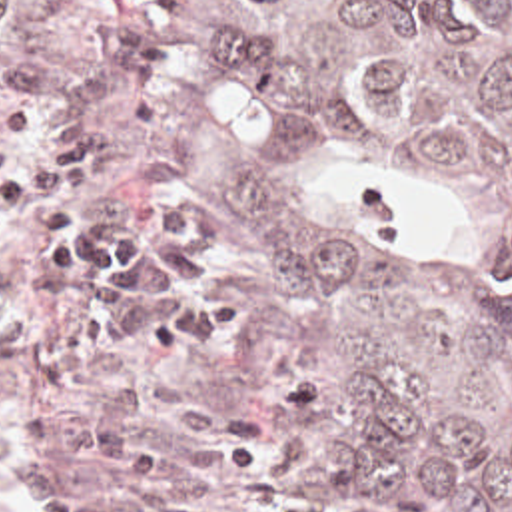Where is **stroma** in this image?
<instances>
[{
  "label": "stroma",
  "mask_w": 512,
  "mask_h": 512,
  "mask_svg": "<svg viewBox=\"0 0 512 512\" xmlns=\"http://www.w3.org/2000/svg\"><path fill=\"white\" fill-rule=\"evenodd\" d=\"M113 14L137 16L147 26L158 69L105 139L143 97L154 101L156 117L145 137L97 171L91 203L158 197L194 211L208 225L214 257L242 299L236 323L208 345L164 347L119 369L89 371L95 383H127L145 391L149 415L137 429L135 449H150L186 399L218 395L244 409L264 443L262 469L216 491L218 512H324L342 503L370 512H424L364 447L338 433L300 427L258 401L254 305L262 289V239L216 207L168 153L190 131H234L346 201L386 255L408 267L444 261V235L382 203L372 161L360 151L314 133L268 97L226 39L222 18L198 0H5L0 93L41 26L53 22L75 51ZM93 481L95 465L81 451L75 397L21 369L0 367V512H37L51 493L91 489Z\"/></svg>",
  "instance_id": "stroma-1"
}]
</instances>
